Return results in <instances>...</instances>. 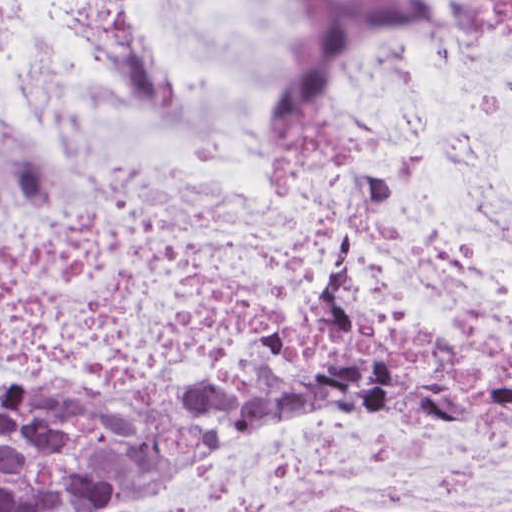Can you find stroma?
Wrapping results in <instances>:
<instances>
[{
    "mask_svg": "<svg viewBox=\"0 0 512 512\" xmlns=\"http://www.w3.org/2000/svg\"><path fill=\"white\" fill-rule=\"evenodd\" d=\"M269 396H274V395L265 394L262 397L255 400L254 402L250 403L244 409V411L224 431H222L211 443H213L215 440H217L225 432L229 431L243 416H245L248 412H250L254 407H256L258 404H260L262 401H264ZM0 512H1V377H0Z\"/></svg>",
    "mask_w": 512,
    "mask_h": 512,
    "instance_id": "35a3bbf8",
    "label": "stroma"
}]
</instances>
